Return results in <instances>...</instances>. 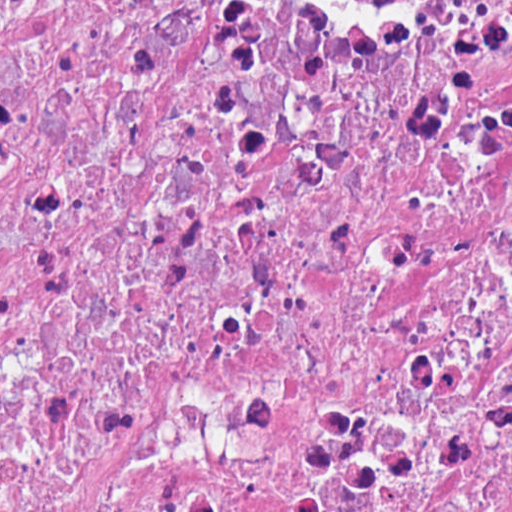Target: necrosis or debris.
I'll list each match as a JSON object with an SVG mask.
<instances>
[{"label": "necrosis or debris", "mask_w": 512, "mask_h": 512, "mask_svg": "<svg viewBox=\"0 0 512 512\" xmlns=\"http://www.w3.org/2000/svg\"><path fill=\"white\" fill-rule=\"evenodd\" d=\"M1 512H512V0H1Z\"/></svg>", "instance_id": "obj_1"}]
</instances>
